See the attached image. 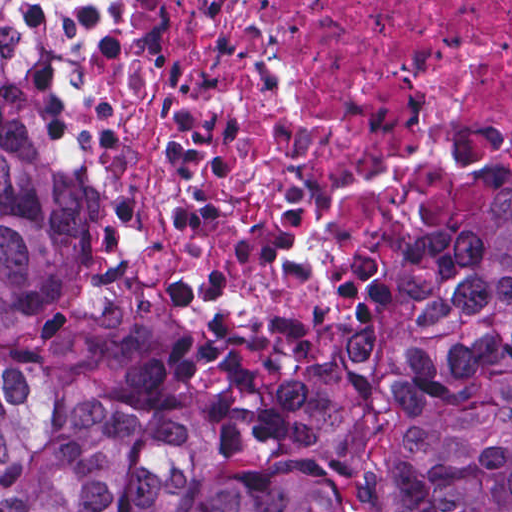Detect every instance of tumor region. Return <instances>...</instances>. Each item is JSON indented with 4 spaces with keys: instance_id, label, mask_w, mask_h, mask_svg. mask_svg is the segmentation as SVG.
<instances>
[{
    "instance_id": "obj_1",
    "label": "tumor region",
    "mask_w": 512,
    "mask_h": 512,
    "mask_svg": "<svg viewBox=\"0 0 512 512\" xmlns=\"http://www.w3.org/2000/svg\"><path fill=\"white\" fill-rule=\"evenodd\" d=\"M79 187L0 9V334L82 285ZM0 512H512V185L411 256L358 346L213 417L0 355Z\"/></svg>"
}]
</instances>
